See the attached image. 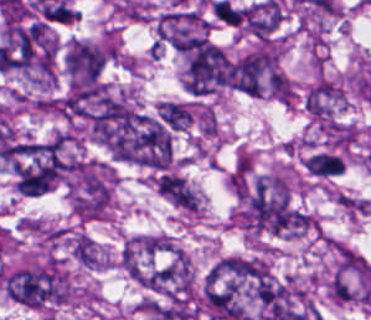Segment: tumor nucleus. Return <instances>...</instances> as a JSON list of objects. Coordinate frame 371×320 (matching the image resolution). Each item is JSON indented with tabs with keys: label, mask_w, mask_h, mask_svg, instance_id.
I'll return each instance as SVG.
<instances>
[{
	"label": "tumor nucleus",
	"mask_w": 371,
	"mask_h": 320,
	"mask_svg": "<svg viewBox=\"0 0 371 320\" xmlns=\"http://www.w3.org/2000/svg\"><path fill=\"white\" fill-rule=\"evenodd\" d=\"M71 186L74 208L79 217H105L111 200L112 186L103 167L79 161Z\"/></svg>",
	"instance_id": "2f306a5c"
},
{
	"label": "tumor nucleus",
	"mask_w": 371,
	"mask_h": 320,
	"mask_svg": "<svg viewBox=\"0 0 371 320\" xmlns=\"http://www.w3.org/2000/svg\"><path fill=\"white\" fill-rule=\"evenodd\" d=\"M225 69L221 49L203 40L189 54L184 89L191 94H207L224 84Z\"/></svg>",
	"instance_id": "8643909e"
},
{
	"label": "tumor nucleus",
	"mask_w": 371,
	"mask_h": 320,
	"mask_svg": "<svg viewBox=\"0 0 371 320\" xmlns=\"http://www.w3.org/2000/svg\"><path fill=\"white\" fill-rule=\"evenodd\" d=\"M145 285L169 298L187 295L190 266L183 255H176L144 276Z\"/></svg>",
	"instance_id": "5ab6c2c4"
},
{
	"label": "tumor nucleus",
	"mask_w": 371,
	"mask_h": 320,
	"mask_svg": "<svg viewBox=\"0 0 371 320\" xmlns=\"http://www.w3.org/2000/svg\"><path fill=\"white\" fill-rule=\"evenodd\" d=\"M107 50L73 41L65 54V70L71 81L100 80Z\"/></svg>",
	"instance_id": "2cbd58db"
},
{
	"label": "tumor nucleus",
	"mask_w": 371,
	"mask_h": 320,
	"mask_svg": "<svg viewBox=\"0 0 371 320\" xmlns=\"http://www.w3.org/2000/svg\"><path fill=\"white\" fill-rule=\"evenodd\" d=\"M156 188L164 198L177 207L195 211L198 197L183 176L175 172H162L157 176Z\"/></svg>",
	"instance_id": "3d1891a8"
},
{
	"label": "tumor nucleus",
	"mask_w": 371,
	"mask_h": 320,
	"mask_svg": "<svg viewBox=\"0 0 371 320\" xmlns=\"http://www.w3.org/2000/svg\"><path fill=\"white\" fill-rule=\"evenodd\" d=\"M281 8L277 1H264L248 7L244 26L256 38H270L280 23Z\"/></svg>",
	"instance_id": "2083b535"
},
{
	"label": "tumor nucleus",
	"mask_w": 371,
	"mask_h": 320,
	"mask_svg": "<svg viewBox=\"0 0 371 320\" xmlns=\"http://www.w3.org/2000/svg\"><path fill=\"white\" fill-rule=\"evenodd\" d=\"M304 167L310 176L330 178L343 172V161L335 152L316 151L306 157Z\"/></svg>",
	"instance_id": "8087334f"
},
{
	"label": "tumor nucleus",
	"mask_w": 371,
	"mask_h": 320,
	"mask_svg": "<svg viewBox=\"0 0 371 320\" xmlns=\"http://www.w3.org/2000/svg\"><path fill=\"white\" fill-rule=\"evenodd\" d=\"M159 120L170 130H183L193 119L189 106L183 102L162 101L157 106Z\"/></svg>",
	"instance_id": "c2bd9aea"
}]
</instances>
